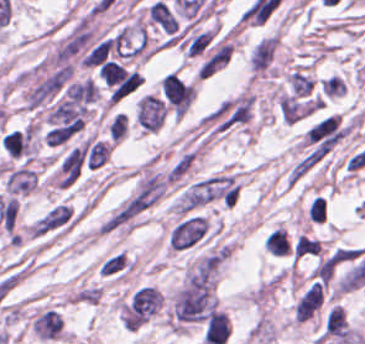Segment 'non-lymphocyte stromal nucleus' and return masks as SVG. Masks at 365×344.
<instances>
[{
    "label": "non-lymphocyte stromal nucleus",
    "mask_w": 365,
    "mask_h": 344,
    "mask_svg": "<svg viewBox=\"0 0 365 344\" xmlns=\"http://www.w3.org/2000/svg\"><path fill=\"white\" fill-rule=\"evenodd\" d=\"M209 222L202 213L184 212L171 227L166 241L169 249L184 251L204 242Z\"/></svg>",
    "instance_id": "non-lymphocyte-stromal-nucleus-1"
},
{
    "label": "non-lymphocyte stromal nucleus",
    "mask_w": 365,
    "mask_h": 344,
    "mask_svg": "<svg viewBox=\"0 0 365 344\" xmlns=\"http://www.w3.org/2000/svg\"><path fill=\"white\" fill-rule=\"evenodd\" d=\"M279 35L261 37L249 50L248 68L252 77H271L277 63Z\"/></svg>",
    "instance_id": "non-lymphocyte-stromal-nucleus-2"
},
{
    "label": "non-lymphocyte stromal nucleus",
    "mask_w": 365,
    "mask_h": 344,
    "mask_svg": "<svg viewBox=\"0 0 365 344\" xmlns=\"http://www.w3.org/2000/svg\"><path fill=\"white\" fill-rule=\"evenodd\" d=\"M29 329L41 341H56L62 337L64 319L57 308L45 306L30 317Z\"/></svg>",
    "instance_id": "non-lymphocyte-stromal-nucleus-3"
},
{
    "label": "non-lymphocyte stromal nucleus",
    "mask_w": 365,
    "mask_h": 344,
    "mask_svg": "<svg viewBox=\"0 0 365 344\" xmlns=\"http://www.w3.org/2000/svg\"><path fill=\"white\" fill-rule=\"evenodd\" d=\"M164 115V101L151 93H144L135 107L137 124L146 131L159 129Z\"/></svg>",
    "instance_id": "non-lymphocyte-stromal-nucleus-4"
},
{
    "label": "non-lymphocyte stromal nucleus",
    "mask_w": 365,
    "mask_h": 344,
    "mask_svg": "<svg viewBox=\"0 0 365 344\" xmlns=\"http://www.w3.org/2000/svg\"><path fill=\"white\" fill-rule=\"evenodd\" d=\"M97 269L102 276L120 278L128 273L129 259L123 251H115L104 257Z\"/></svg>",
    "instance_id": "non-lymphocyte-stromal-nucleus-5"
},
{
    "label": "non-lymphocyte stromal nucleus",
    "mask_w": 365,
    "mask_h": 344,
    "mask_svg": "<svg viewBox=\"0 0 365 344\" xmlns=\"http://www.w3.org/2000/svg\"><path fill=\"white\" fill-rule=\"evenodd\" d=\"M83 149L87 167H96L108 159L110 148L107 141L98 139H86L83 143Z\"/></svg>",
    "instance_id": "non-lymphocyte-stromal-nucleus-6"
}]
</instances>
